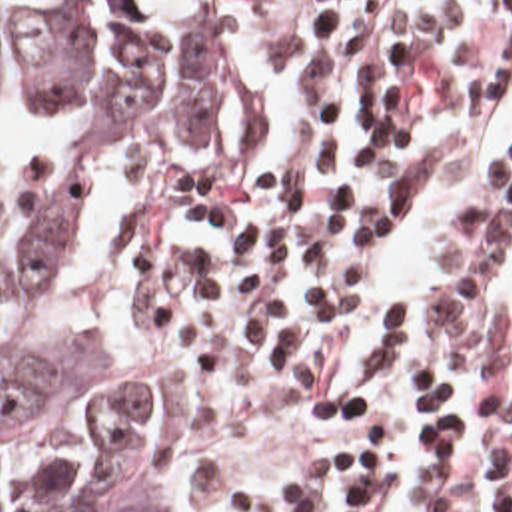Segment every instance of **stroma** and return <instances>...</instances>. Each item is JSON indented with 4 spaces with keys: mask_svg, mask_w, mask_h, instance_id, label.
<instances>
[{
    "mask_svg": "<svg viewBox=\"0 0 512 512\" xmlns=\"http://www.w3.org/2000/svg\"><path fill=\"white\" fill-rule=\"evenodd\" d=\"M423 2L429 0H223L229 22L223 106L249 76L311 36L327 28L375 18ZM111 168L117 180L115 258L121 270L123 306L131 324L151 340V320L165 256V212L185 164H93L87 182ZM129 360L153 368L151 352L143 358ZM155 456L175 481V512L205 511L175 468L163 432L155 444Z\"/></svg>",
    "mask_w": 512,
    "mask_h": 512,
    "instance_id": "35a3bbf8",
    "label": "stroma"
}]
</instances>
